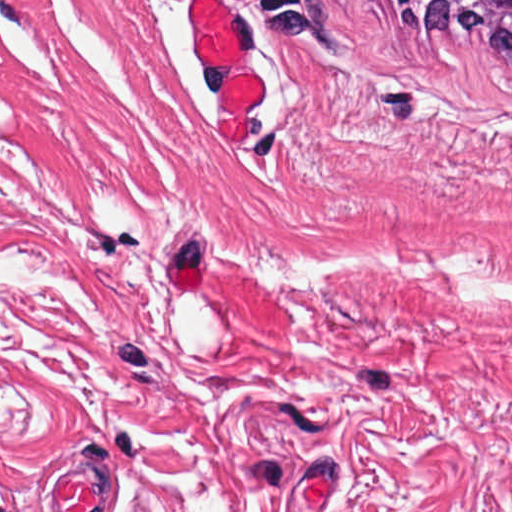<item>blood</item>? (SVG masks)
<instances>
[{
	"instance_id": "1",
	"label": "blood",
	"mask_w": 512,
	"mask_h": 512,
	"mask_svg": "<svg viewBox=\"0 0 512 512\" xmlns=\"http://www.w3.org/2000/svg\"><path fill=\"white\" fill-rule=\"evenodd\" d=\"M188 12L196 50L214 86L216 140H240L258 106V72L247 58L251 37L219 0H193Z\"/></svg>"
}]
</instances>
